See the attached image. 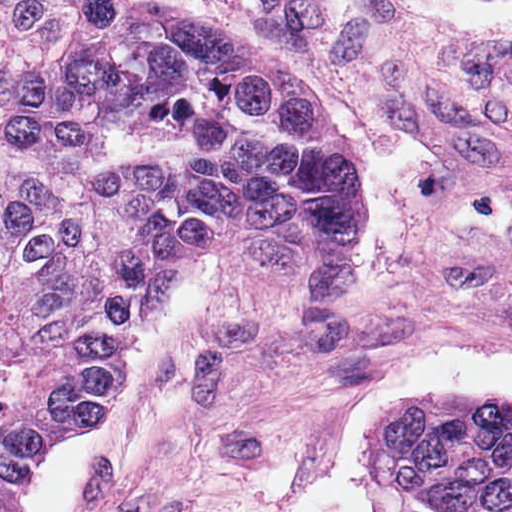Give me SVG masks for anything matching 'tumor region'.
<instances>
[{
    "mask_svg": "<svg viewBox=\"0 0 512 512\" xmlns=\"http://www.w3.org/2000/svg\"><path fill=\"white\" fill-rule=\"evenodd\" d=\"M360 246L359 171L287 59L130 0H0V329L51 444L108 413L189 263L324 291ZM376 446L426 512H512V404L432 396Z\"/></svg>",
    "mask_w": 512,
    "mask_h": 512,
    "instance_id": "1",
    "label": "tumor region"
}]
</instances>
